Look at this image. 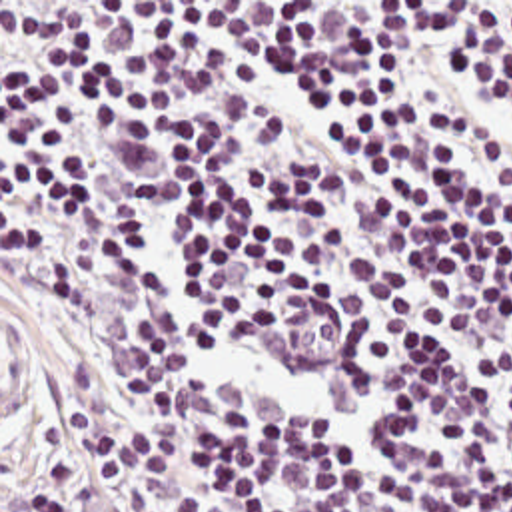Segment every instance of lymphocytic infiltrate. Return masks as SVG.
I'll return each mask as SVG.
<instances>
[{"label":"lymphocytic infiltrate","instance_id":"obj_1","mask_svg":"<svg viewBox=\"0 0 512 512\" xmlns=\"http://www.w3.org/2000/svg\"><path fill=\"white\" fill-rule=\"evenodd\" d=\"M4 248L78 321L28 512H512V192Z\"/></svg>","mask_w":512,"mask_h":512}]
</instances>
